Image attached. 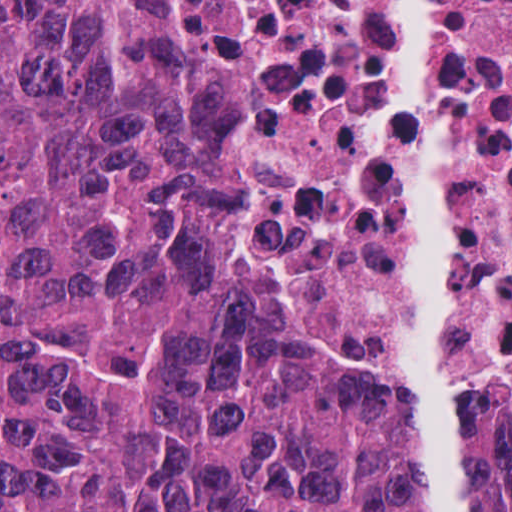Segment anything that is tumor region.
Masks as SVG:
<instances>
[{"mask_svg": "<svg viewBox=\"0 0 512 512\" xmlns=\"http://www.w3.org/2000/svg\"><path fill=\"white\" fill-rule=\"evenodd\" d=\"M196 104L178 0H0V512H420L407 422L267 352ZM461 412L468 512H512V420Z\"/></svg>", "mask_w": 512, "mask_h": 512, "instance_id": "e687c5a6", "label": "tumor region"}]
</instances>
